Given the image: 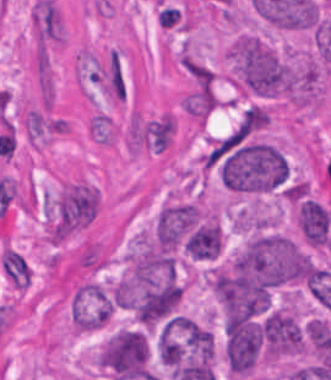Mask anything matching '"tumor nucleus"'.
Masks as SVG:
<instances>
[{
	"mask_svg": "<svg viewBox=\"0 0 331 380\" xmlns=\"http://www.w3.org/2000/svg\"><path fill=\"white\" fill-rule=\"evenodd\" d=\"M263 338L259 324L230 316L226 326V356L235 372H248L256 366L262 352Z\"/></svg>",
	"mask_w": 331,
	"mask_h": 380,
	"instance_id": "3",
	"label": "tumor nucleus"
},
{
	"mask_svg": "<svg viewBox=\"0 0 331 380\" xmlns=\"http://www.w3.org/2000/svg\"><path fill=\"white\" fill-rule=\"evenodd\" d=\"M261 332L268 354L278 357L301 352L300 326L291 314L273 310L268 314Z\"/></svg>",
	"mask_w": 331,
	"mask_h": 380,
	"instance_id": "4",
	"label": "tumor nucleus"
},
{
	"mask_svg": "<svg viewBox=\"0 0 331 380\" xmlns=\"http://www.w3.org/2000/svg\"><path fill=\"white\" fill-rule=\"evenodd\" d=\"M296 219L306 242L312 245H326L331 212L323 204L310 198L303 200Z\"/></svg>",
	"mask_w": 331,
	"mask_h": 380,
	"instance_id": "5",
	"label": "tumor nucleus"
},
{
	"mask_svg": "<svg viewBox=\"0 0 331 380\" xmlns=\"http://www.w3.org/2000/svg\"><path fill=\"white\" fill-rule=\"evenodd\" d=\"M233 80L258 97L290 98L294 71L269 43L252 34H239L228 50Z\"/></svg>",
	"mask_w": 331,
	"mask_h": 380,
	"instance_id": "1",
	"label": "tumor nucleus"
},
{
	"mask_svg": "<svg viewBox=\"0 0 331 380\" xmlns=\"http://www.w3.org/2000/svg\"><path fill=\"white\" fill-rule=\"evenodd\" d=\"M149 346L139 328H120L101 342L95 361L107 380L146 372Z\"/></svg>",
	"mask_w": 331,
	"mask_h": 380,
	"instance_id": "2",
	"label": "tumor nucleus"
}]
</instances>
